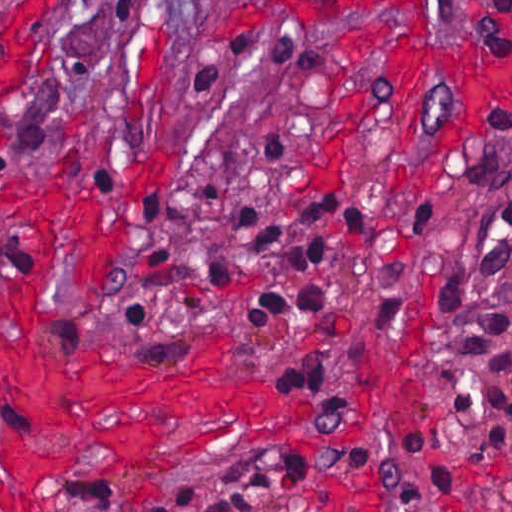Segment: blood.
Segmentation results:
<instances>
[{
    "mask_svg": "<svg viewBox=\"0 0 512 512\" xmlns=\"http://www.w3.org/2000/svg\"><path fill=\"white\" fill-rule=\"evenodd\" d=\"M431 11L432 0H239L230 18L392 19L365 28L358 41L354 67L334 99L326 168L361 123L389 110L396 139L406 142L417 80L432 70L450 87L455 119L406 176L401 197L409 200L444 174L489 112L512 104V73L442 53L431 38ZM5 142L0 116V150ZM0 212L21 221L35 241L18 286L0 290V512H44L42 479L69 468L81 475L172 471L229 438L245 450L296 445L329 453L369 434L367 393L358 428L322 429L311 426L309 403L261 383L220 381L238 355L229 341L204 343L192 364L180 368L39 345L40 321L57 307L51 266L58 249L67 250L76 283L100 284L123 248L126 217L105 214L96 194L68 196L58 183L6 180H0Z\"/></svg>",
    "mask_w": 512,
    "mask_h": 512,
    "instance_id": "blood-1",
    "label": "blood"
}]
</instances>
